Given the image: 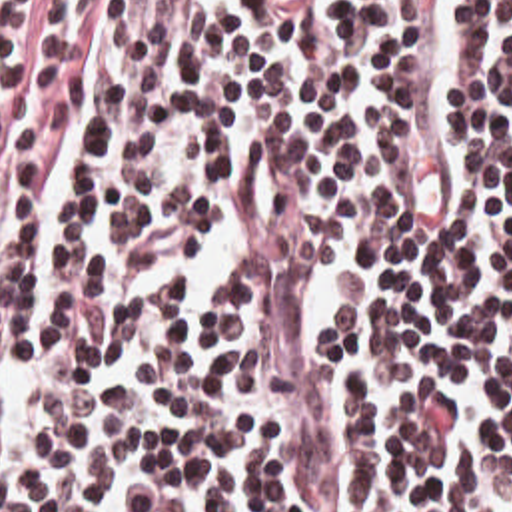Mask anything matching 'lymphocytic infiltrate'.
I'll return each instance as SVG.
<instances>
[{
    "label": "lymphocytic infiltrate",
    "instance_id": "lymphocytic-infiltrate-1",
    "mask_svg": "<svg viewBox=\"0 0 512 512\" xmlns=\"http://www.w3.org/2000/svg\"><path fill=\"white\" fill-rule=\"evenodd\" d=\"M0 512H512V0H0Z\"/></svg>",
    "mask_w": 512,
    "mask_h": 512
}]
</instances>
